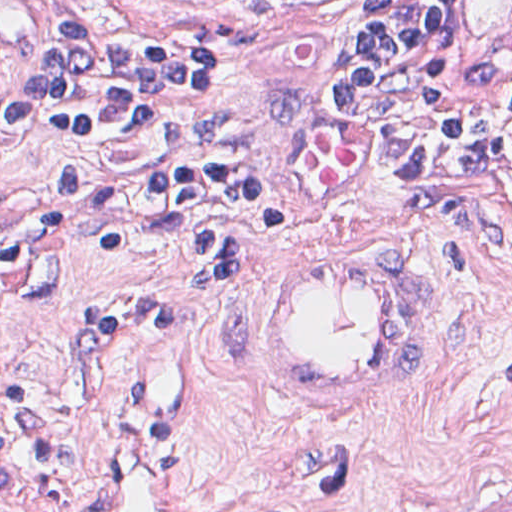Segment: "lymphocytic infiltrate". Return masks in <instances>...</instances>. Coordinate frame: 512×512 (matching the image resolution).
<instances>
[{"mask_svg":"<svg viewBox=\"0 0 512 512\" xmlns=\"http://www.w3.org/2000/svg\"><path fill=\"white\" fill-rule=\"evenodd\" d=\"M217 90L209 49L116 36L63 0H1V163L26 130L54 147L100 146L66 180L1 196V261L42 250L68 221L139 197L149 224L182 238L204 283L253 271L289 243L272 186L242 163L200 165L120 142L177 125ZM330 114L435 120L452 173L430 184H495L512 158V29H490L460 0H367Z\"/></svg>","mask_w":512,"mask_h":512,"instance_id":"lymphocytic-infiltrate-1","label":"lymphocytic infiltrate"}]
</instances>
